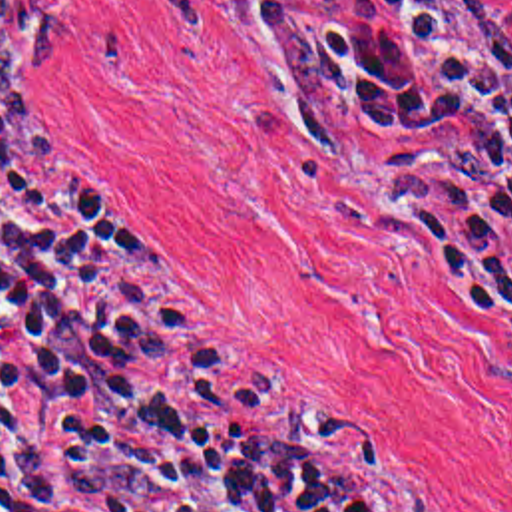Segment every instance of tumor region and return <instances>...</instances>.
Masks as SVG:
<instances>
[{"label": "tumor region", "mask_w": 512, "mask_h": 512, "mask_svg": "<svg viewBox=\"0 0 512 512\" xmlns=\"http://www.w3.org/2000/svg\"><path fill=\"white\" fill-rule=\"evenodd\" d=\"M53 51V5L0 0V115H29L33 63Z\"/></svg>", "instance_id": "1"}]
</instances>
